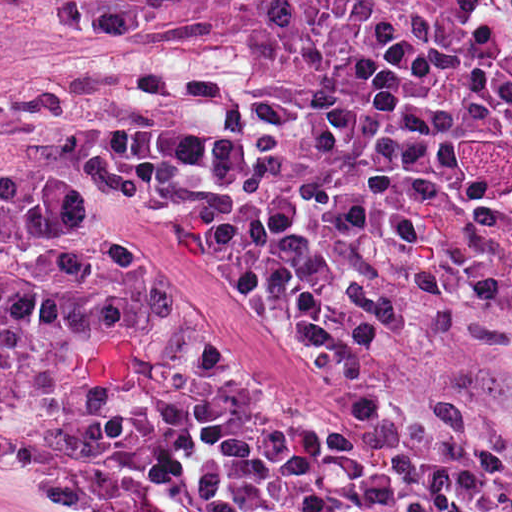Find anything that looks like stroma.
<instances>
[{
	"label": "stroma",
	"instance_id": "35a3bbf8",
	"mask_svg": "<svg viewBox=\"0 0 512 512\" xmlns=\"http://www.w3.org/2000/svg\"><path fill=\"white\" fill-rule=\"evenodd\" d=\"M264 0H0V214L108 242L195 365L287 419L345 429L336 382L293 293L141 192L49 139L18 101L55 77L243 70ZM0 490L69 512H312L251 489H71L0 433Z\"/></svg>",
	"mask_w": 512,
	"mask_h": 512
}]
</instances>
